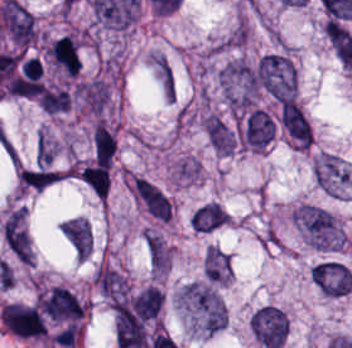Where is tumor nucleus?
Segmentation results:
<instances>
[{
  "label": "tumor nucleus",
  "mask_w": 352,
  "mask_h": 348,
  "mask_svg": "<svg viewBox=\"0 0 352 348\" xmlns=\"http://www.w3.org/2000/svg\"><path fill=\"white\" fill-rule=\"evenodd\" d=\"M257 78L262 90L273 98H294V70L280 53H266L259 58Z\"/></svg>",
  "instance_id": "2f306a5c"
},
{
  "label": "tumor nucleus",
  "mask_w": 352,
  "mask_h": 348,
  "mask_svg": "<svg viewBox=\"0 0 352 348\" xmlns=\"http://www.w3.org/2000/svg\"><path fill=\"white\" fill-rule=\"evenodd\" d=\"M184 299L206 332L222 328L223 306L215 291L205 283H192L184 287Z\"/></svg>",
  "instance_id": "8643909e"
},
{
  "label": "tumor nucleus",
  "mask_w": 352,
  "mask_h": 348,
  "mask_svg": "<svg viewBox=\"0 0 352 348\" xmlns=\"http://www.w3.org/2000/svg\"><path fill=\"white\" fill-rule=\"evenodd\" d=\"M254 338L266 348H278L287 330L288 319L275 305H261L249 319Z\"/></svg>",
  "instance_id": "5ab6c2c4"
},
{
  "label": "tumor nucleus",
  "mask_w": 352,
  "mask_h": 348,
  "mask_svg": "<svg viewBox=\"0 0 352 348\" xmlns=\"http://www.w3.org/2000/svg\"><path fill=\"white\" fill-rule=\"evenodd\" d=\"M3 326L16 337H38L45 334L39 310L31 305L8 303L0 310Z\"/></svg>",
  "instance_id": "2cbd58db"
},
{
  "label": "tumor nucleus",
  "mask_w": 352,
  "mask_h": 348,
  "mask_svg": "<svg viewBox=\"0 0 352 348\" xmlns=\"http://www.w3.org/2000/svg\"><path fill=\"white\" fill-rule=\"evenodd\" d=\"M309 276L324 293H348L352 285L349 268L332 259L317 261L309 270Z\"/></svg>",
  "instance_id": "3d1891a8"
},
{
  "label": "tumor nucleus",
  "mask_w": 352,
  "mask_h": 348,
  "mask_svg": "<svg viewBox=\"0 0 352 348\" xmlns=\"http://www.w3.org/2000/svg\"><path fill=\"white\" fill-rule=\"evenodd\" d=\"M275 126L268 112L252 107L240 124V140L252 150H260L274 135Z\"/></svg>",
  "instance_id": "2083b535"
},
{
  "label": "tumor nucleus",
  "mask_w": 352,
  "mask_h": 348,
  "mask_svg": "<svg viewBox=\"0 0 352 348\" xmlns=\"http://www.w3.org/2000/svg\"><path fill=\"white\" fill-rule=\"evenodd\" d=\"M278 118L294 144L308 146L310 142L309 121L293 97H285L282 100Z\"/></svg>",
  "instance_id": "8087334f"
},
{
  "label": "tumor nucleus",
  "mask_w": 352,
  "mask_h": 348,
  "mask_svg": "<svg viewBox=\"0 0 352 348\" xmlns=\"http://www.w3.org/2000/svg\"><path fill=\"white\" fill-rule=\"evenodd\" d=\"M294 218L311 245H324L330 228L329 212L318 207L299 206Z\"/></svg>",
  "instance_id": "c2bd9aea"
},
{
  "label": "tumor nucleus",
  "mask_w": 352,
  "mask_h": 348,
  "mask_svg": "<svg viewBox=\"0 0 352 348\" xmlns=\"http://www.w3.org/2000/svg\"><path fill=\"white\" fill-rule=\"evenodd\" d=\"M41 309L53 319H77L81 307L67 289L53 287L39 297Z\"/></svg>",
  "instance_id": "feef74b5"
},
{
  "label": "tumor nucleus",
  "mask_w": 352,
  "mask_h": 348,
  "mask_svg": "<svg viewBox=\"0 0 352 348\" xmlns=\"http://www.w3.org/2000/svg\"><path fill=\"white\" fill-rule=\"evenodd\" d=\"M134 188L139 201L146 211L155 217L170 218V202L159 187L150 180L138 177Z\"/></svg>",
  "instance_id": "3e47fb67"
},
{
  "label": "tumor nucleus",
  "mask_w": 352,
  "mask_h": 348,
  "mask_svg": "<svg viewBox=\"0 0 352 348\" xmlns=\"http://www.w3.org/2000/svg\"><path fill=\"white\" fill-rule=\"evenodd\" d=\"M150 65L159 90L165 101H175L176 85L174 69L166 54L153 52L149 57Z\"/></svg>",
  "instance_id": "f7901128"
},
{
  "label": "tumor nucleus",
  "mask_w": 352,
  "mask_h": 348,
  "mask_svg": "<svg viewBox=\"0 0 352 348\" xmlns=\"http://www.w3.org/2000/svg\"><path fill=\"white\" fill-rule=\"evenodd\" d=\"M65 239L77 257H85L89 253L91 228L86 221L72 217L61 230Z\"/></svg>",
  "instance_id": "268c6acd"
},
{
  "label": "tumor nucleus",
  "mask_w": 352,
  "mask_h": 348,
  "mask_svg": "<svg viewBox=\"0 0 352 348\" xmlns=\"http://www.w3.org/2000/svg\"><path fill=\"white\" fill-rule=\"evenodd\" d=\"M204 132L210 145L223 154H231L235 140L229 126L216 115H208Z\"/></svg>",
  "instance_id": "1edb0cf7"
},
{
  "label": "tumor nucleus",
  "mask_w": 352,
  "mask_h": 348,
  "mask_svg": "<svg viewBox=\"0 0 352 348\" xmlns=\"http://www.w3.org/2000/svg\"><path fill=\"white\" fill-rule=\"evenodd\" d=\"M226 218V212L216 203L204 202L199 205L189 218V224L194 231L208 232L221 225Z\"/></svg>",
  "instance_id": "962dda3e"
},
{
  "label": "tumor nucleus",
  "mask_w": 352,
  "mask_h": 348,
  "mask_svg": "<svg viewBox=\"0 0 352 348\" xmlns=\"http://www.w3.org/2000/svg\"><path fill=\"white\" fill-rule=\"evenodd\" d=\"M52 60L68 74H75L79 67V58L75 43L66 36L57 39L49 51Z\"/></svg>",
  "instance_id": "80c4ae96"
},
{
  "label": "tumor nucleus",
  "mask_w": 352,
  "mask_h": 348,
  "mask_svg": "<svg viewBox=\"0 0 352 348\" xmlns=\"http://www.w3.org/2000/svg\"><path fill=\"white\" fill-rule=\"evenodd\" d=\"M21 187L41 190L59 180V173L46 165H34L18 172Z\"/></svg>",
  "instance_id": "3d7bf9ca"
},
{
  "label": "tumor nucleus",
  "mask_w": 352,
  "mask_h": 348,
  "mask_svg": "<svg viewBox=\"0 0 352 348\" xmlns=\"http://www.w3.org/2000/svg\"><path fill=\"white\" fill-rule=\"evenodd\" d=\"M162 298L163 294L161 290L154 285H146L130 300L147 319L156 314Z\"/></svg>",
  "instance_id": "b15415a9"
},
{
  "label": "tumor nucleus",
  "mask_w": 352,
  "mask_h": 348,
  "mask_svg": "<svg viewBox=\"0 0 352 348\" xmlns=\"http://www.w3.org/2000/svg\"><path fill=\"white\" fill-rule=\"evenodd\" d=\"M80 178L97 198L104 199L107 186L106 165L98 163L86 165L81 172Z\"/></svg>",
  "instance_id": "c6f8f39e"
},
{
  "label": "tumor nucleus",
  "mask_w": 352,
  "mask_h": 348,
  "mask_svg": "<svg viewBox=\"0 0 352 348\" xmlns=\"http://www.w3.org/2000/svg\"><path fill=\"white\" fill-rule=\"evenodd\" d=\"M92 136L97 152L112 163L116 147V138L113 131L98 120L93 127Z\"/></svg>",
  "instance_id": "0710647a"
},
{
  "label": "tumor nucleus",
  "mask_w": 352,
  "mask_h": 348,
  "mask_svg": "<svg viewBox=\"0 0 352 348\" xmlns=\"http://www.w3.org/2000/svg\"><path fill=\"white\" fill-rule=\"evenodd\" d=\"M39 104L45 111H56L68 106V92L60 88H44L39 95Z\"/></svg>",
  "instance_id": "a25b35c7"
},
{
  "label": "tumor nucleus",
  "mask_w": 352,
  "mask_h": 348,
  "mask_svg": "<svg viewBox=\"0 0 352 348\" xmlns=\"http://www.w3.org/2000/svg\"><path fill=\"white\" fill-rule=\"evenodd\" d=\"M146 243L151 266L161 269L165 266L168 252L160 237L146 233Z\"/></svg>",
  "instance_id": "5523d5ea"
},
{
  "label": "tumor nucleus",
  "mask_w": 352,
  "mask_h": 348,
  "mask_svg": "<svg viewBox=\"0 0 352 348\" xmlns=\"http://www.w3.org/2000/svg\"><path fill=\"white\" fill-rule=\"evenodd\" d=\"M202 270L204 277L218 280H224L228 274V270L216 259L204 252Z\"/></svg>",
  "instance_id": "1bfdd9f4"
}]
</instances>
